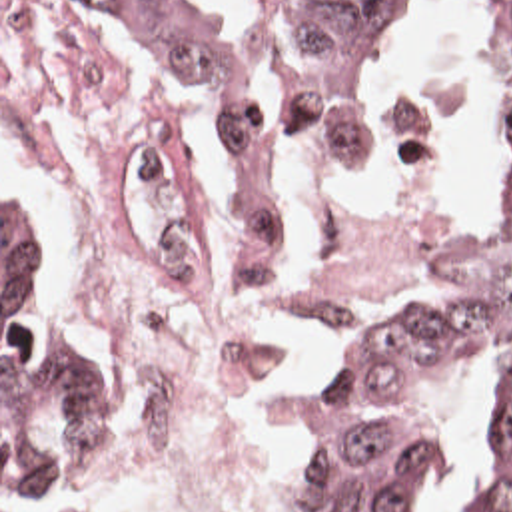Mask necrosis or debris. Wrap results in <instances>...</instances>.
I'll list each match as a JSON object with an SVG mask.
<instances>
[{
    "label": "necrosis or debris",
    "mask_w": 512,
    "mask_h": 512,
    "mask_svg": "<svg viewBox=\"0 0 512 512\" xmlns=\"http://www.w3.org/2000/svg\"><path fill=\"white\" fill-rule=\"evenodd\" d=\"M2 133L134 371L132 466L68 512H294L315 367L399 269L463 245L457 211L345 205L282 239L246 291L206 283L166 109L84 0H2Z\"/></svg>",
    "instance_id": "obj_1"
}]
</instances>
